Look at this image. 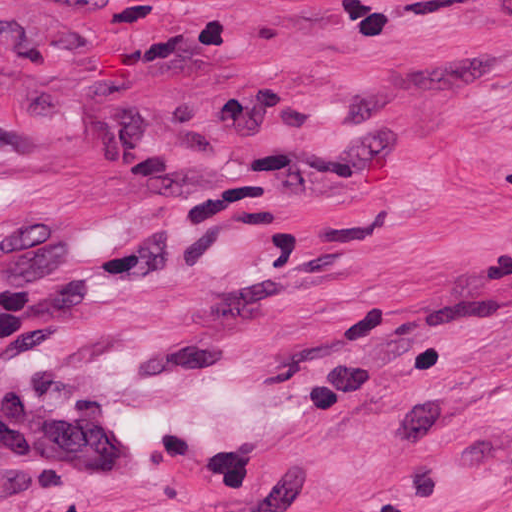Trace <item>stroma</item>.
I'll use <instances>...</instances> for the list:
<instances>
[{
    "mask_svg": "<svg viewBox=\"0 0 512 512\" xmlns=\"http://www.w3.org/2000/svg\"><path fill=\"white\" fill-rule=\"evenodd\" d=\"M0 512H512V0H0Z\"/></svg>",
    "mask_w": 512,
    "mask_h": 512,
    "instance_id": "35a3bbf8",
    "label": "stroma"
}]
</instances>
